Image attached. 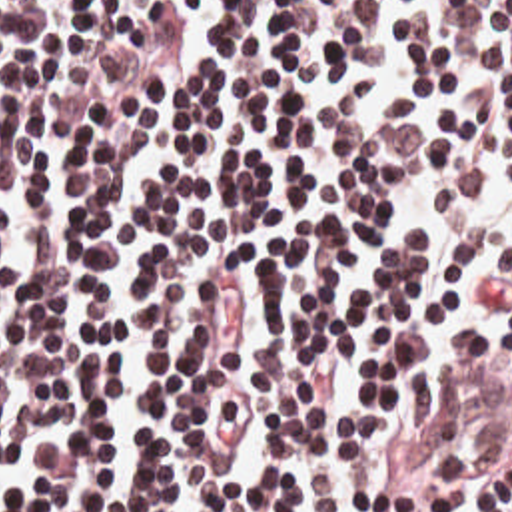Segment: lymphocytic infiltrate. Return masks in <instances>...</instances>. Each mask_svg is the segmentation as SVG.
Returning <instances> with one entry per match:
<instances>
[{"instance_id": "f902f5d3", "label": "lymphocytic infiltrate", "mask_w": 512, "mask_h": 512, "mask_svg": "<svg viewBox=\"0 0 512 512\" xmlns=\"http://www.w3.org/2000/svg\"><path fill=\"white\" fill-rule=\"evenodd\" d=\"M512 512V0H0V512Z\"/></svg>"}]
</instances>
